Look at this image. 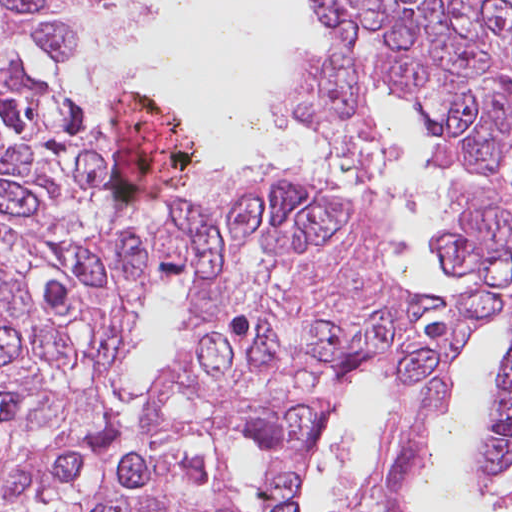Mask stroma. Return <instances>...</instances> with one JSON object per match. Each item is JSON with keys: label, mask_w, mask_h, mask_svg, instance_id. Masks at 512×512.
Segmentation results:
<instances>
[{"label": "stroma", "mask_w": 512, "mask_h": 512, "mask_svg": "<svg viewBox=\"0 0 512 512\" xmlns=\"http://www.w3.org/2000/svg\"><path fill=\"white\" fill-rule=\"evenodd\" d=\"M307 52H309L313 56L323 53L321 51H317V50H313V49H309V50H307ZM292 61H291L290 65L287 67V69L284 71V73L281 75V77L279 78V80L277 81L275 86L273 87V89L271 91V95H272L273 90L276 88V86L287 75L288 71L291 68ZM70 73H71L72 82L82 92V94L87 98V100H88L90 106L92 107L94 113L96 114L98 119L101 121V123L103 124L104 128L106 129V131H107V133H108V135L110 137V142H111V177L113 178V139L120 132L118 131V129H116L114 127L113 123L109 119L110 117L106 120L97 111L93 95H92V93H91L87 83L85 82L83 77L74 69V67L72 65H71V68H70ZM385 92H387V91L376 89L373 92H371L370 94H368L371 106L374 108V110L381 117H382V115H381V111H380V108H379L378 101L380 99L381 94H383ZM270 99H271V96H270ZM157 101L160 103V105L163 107V109L166 111V113L169 115V117L177 125H179L182 129H184L188 133V135H189L188 129L186 128V125H185L184 121L181 120L178 116H176L171 110H169L159 99H157ZM279 119L283 120L284 122H286L287 124L291 125L295 129H298V130L302 131L303 133H305L306 135H308L309 137H311L308 134V132L305 129V127L298 120L289 119V118H279ZM438 160L440 162V165H441V168H442V172H443L444 182L446 184V182H447V168H446L443 160L439 156H438ZM285 163H288V164H291L293 166H296V167L302 168L304 170H307V171L311 172L313 175H315L316 177L326 181L331 187H333L343 197V199L348 204L352 205L353 207L357 208V210L361 211L366 216H368L369 218L373 219L370 211L367 210L365 207H363L357 201V199H355L346 190V188L343 186V184L341 182H339L338 180H336L335 178H333L332 176H330V175H328V174H326V173H324V172H322L320 170H317L315 168H312V167H309V166H306V165H303V164H300V163H296V162H285ZM219 173H221V172H219ZM215 174H218V173H215ZM211 175H214V174H211ZM207 176H210V175H207ZM207 176H204L196 168L195 154H194V166H193L191 172L175 188H172V189H191L194 186H196L197 184H199L202 180H204ZM167 190H169V189H167ZM163 191H165V190H163ZM158 192H161V191H158ZM155 193H157V192H155ZM126 202H138V201H126ZM435 223H434V225H435ZM383 257H384L385 264L389 267L388 261H387V258H386V254H385V251H384V247H383ZM444 269H446V268H444ZM446 270L449 271L455 277L456 272L450 271L448 269H446ZM433 295H448V294H433ZM500 329H501V331L503 333V336L505 338L506 344H505L504 352H503L502 356L500 357V359L498 361L496 372H495V374L493 375V377L491 379V383H490V387H489V391H488V396H489V394L491 392V389L493 387L495 379H496V377H497V375H498V373L500 371V368L502 366V363L504 361L506 350H507V346H508V342H509L505 326L500 327ZM374 381L377 382V384L379 385V387L381 388V390L383 392L384 399H385L386 406H387V410H388V414H389V418H390V422H391V404H390L389 396H388V394H387V392H386V390H385L381 380H376V379H360V380H357V381L353 382V384L351 385V387L347 391V393H346V395H345V397H344V399L342 401V404L340 406V409H339L338 413L335 415V417L332 419V421L329 424L327 432L329 431V429L331 428V426L335 422V420L338 417L339 413L352 402V400L357 396V393L363 388V386L365 384H367V383L374 382ZM444 411L438 413L436 416H434L432 419H430L428 421V423H427V425H426V427L424 429V432H423L419 455H420V452H421V450H422L426 440L428 439V437H429V435H430V433L432 431L433 426L441 418V416L443 415ZM475 438H476V435H475V437H474V439H473V441L471 443L468 455H467V457H466V459H465V461L463 463V466H464L466 474H467V478H468V482H469L471 493L474 495V497L476 499H478L479 497L474 493L472 485H471V452H472V449H473V446H474ZM239 448L250 449L252 454H253V456H254V458H255L257 492H258V499H259V503H260V465H259L256 449L253 446H251L247 441L237 444V446L235 447V450L239 449ZM419 455H418V459H417L415 470H416L417 465H418ZM224 494L227 497V499H229V501L231 503V506H232V509H233V512H239V510H238V508L236 506V503H235V496H234V493H233V489H232V485H231V481H230V477H229L227 466H226V470H225V473H224ZM300 512H301V507H300Z\"/></svg>", "instance_id": "1"}]
</instances>
